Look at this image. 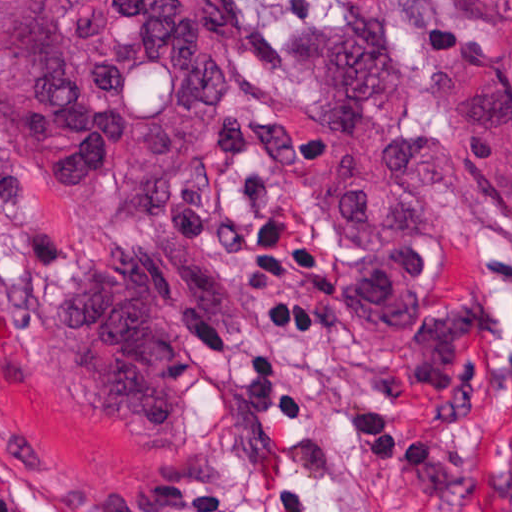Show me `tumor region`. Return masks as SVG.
<instances>
[{
  "instance_id": "1",
  "label": "tumor region",
  "mask_w": 512,
  "mask_h": 512,
  "mask_svg": "<svg viewBox=\"0 0 512 512\" xmlns=\"http://www.w3.org/2000/svg\"><path fill=\"white\" fill-rule=\"evenodd\" d=\"M290 58L239 0H0V339H41L85 404L188 425L179 338L232 314L247 222L291 158L274 134L207 153L226 59ZM87 503L234 512L194 490Z\"/></svg>"
}]
</instances>
